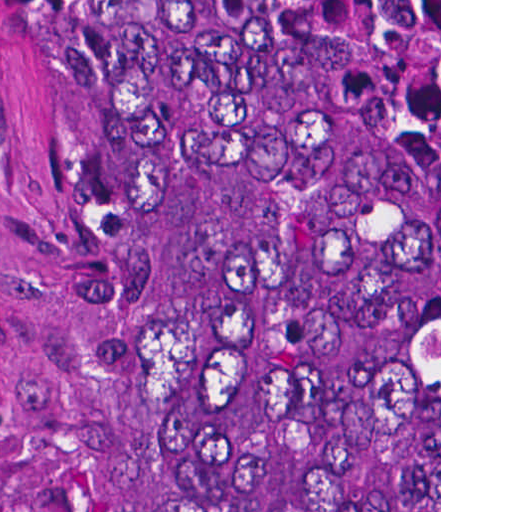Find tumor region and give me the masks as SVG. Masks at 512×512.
<instances>
[{"label": "tumor region", "mask_w": 512, "mask_h": 512, "mask_svg": "<svg viewBox=\"0 0 512 512\" xmlns=\"http://www.w3.org/2000/svg\"><path fill=\"white\" fill-rule=\"evenodd\" d=\"M163 512H439V0H34Z\"/></svg>", "instance_id": "1"}]
</instances>
